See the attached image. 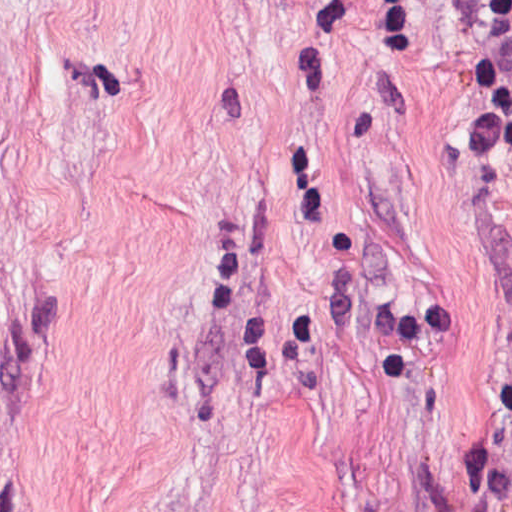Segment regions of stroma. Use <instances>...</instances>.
Listing matches in <instances>:
<instances>
[{
  "instance_id": "1",
  "label": "stroma",
  "mask_w": 512,
  "mask_h": 512,
  "mask_svg": "<svg viewBox=\"0 0 512 512\" xmlns=\"http://www.w3.org/2000/svg\"><path fill=\"white\" fill-rule=\"evenodd\" d=\"M504 350L443 0H0V512H494Z\"/></svg>"
}]
</instances>
